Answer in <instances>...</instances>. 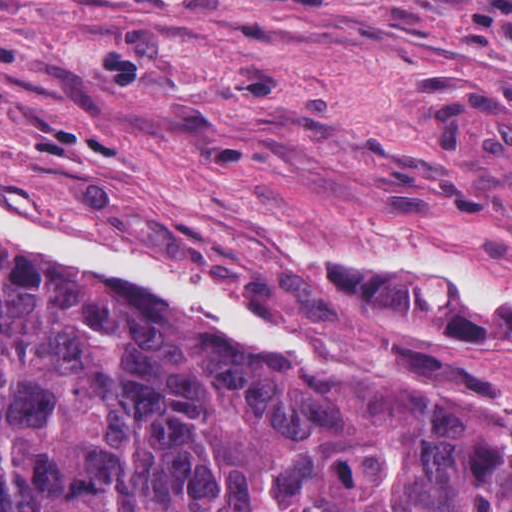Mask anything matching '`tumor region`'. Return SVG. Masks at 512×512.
Instances as JSON below:
<instances>
[{"label":"tumor region","instance_id":"obj_1","mask_svg":"<svg viewBox=\"0 0 512 512\" xmlns=\"http://www.w3.org/2000/svg\"><path fill=\"white\" fill-rule=\"evenodd\" d=\"M0 512H512V409L251 352L0 245Z\"/></svg>","mask_w":512,"mask_h":512}]
</instances>
